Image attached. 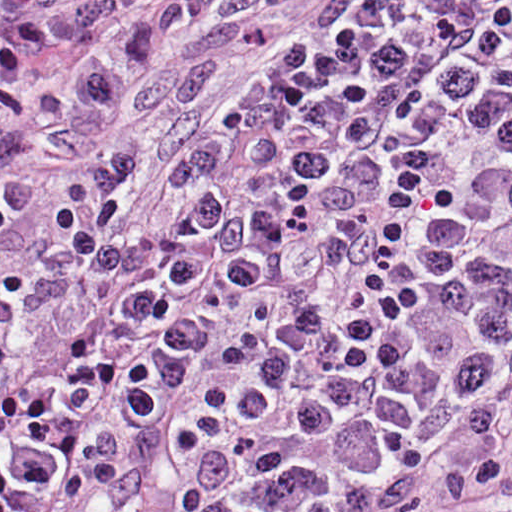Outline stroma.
<instances>
[{
	"instance_id": "1",
	"label": "stroma",
	"mask_w": 512,
	"mask_h": 512,
	"mask_svg": "<svg viewBox=\"0 0 512 512\" xmlns=\"http://www.w3.org/2000/svg\"><path fill=\"white\" fill-rule=\"evenodd\" d=\"M318 0H219L136 100L74 158L42 175L0 230V267L46 251L78 181L111 151L140 150L120 239L170 236L182 152L224 122L247 83ZM335 512H512V320L469 322L421 371L366 445Z\"/></svg>"
}]
</instances>
